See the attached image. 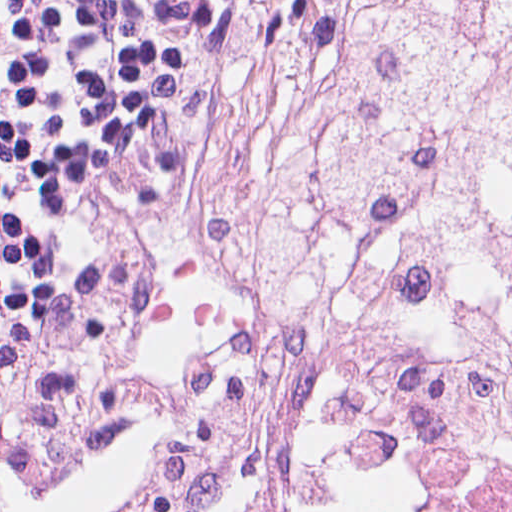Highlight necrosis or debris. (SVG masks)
Returning <instances> with one entry per match:
<instances>
[{
	"instance_id": "1",
	"label": "necrosis or debris",
	"mask_w": 512,
	"mask_h": 512,
	"mask_svg": "<svg viewBox=\"0 0 512 512\" xmlns=\"http://www.w3.org/2000/svg\"><path fill=\"white\" fill-rule=\"evenodd\" d=\"M284 252L172 512H304L350 389L400 374L512 452V0H277Z\"/></svg>"
}]
</instances>
